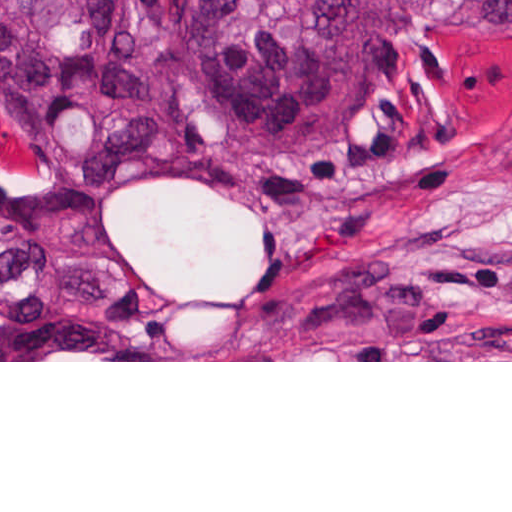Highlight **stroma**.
Wrapping results in <instances>:
<instances>
[{"mask_svg": "<svg viewBox=\"0 0 512 512\" xmlns=\"http://www.w3.org/2000/svg\"><path fill=\"white\" fill-rule=\"evenodd\" d=\"M430 1L370 109L307 152L142 74L169 144L262 194L141 176L90 207L142 325L119 360L0 362H512V36Z\"/></svg>", "mask_w": 512, "mask_h": 512, "instance_id": "1", "label": "stroma"}]
</instances>
